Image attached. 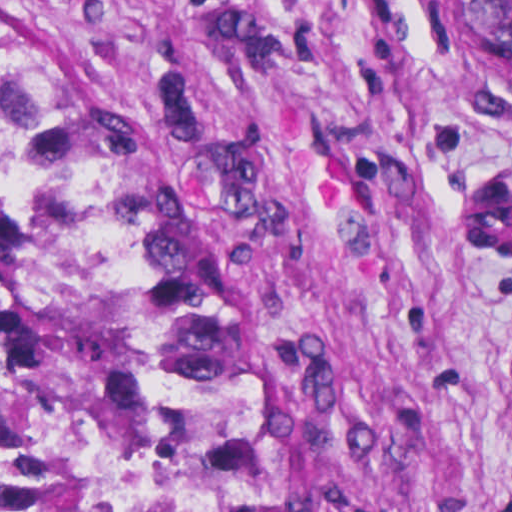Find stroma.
<instances>
[{"label":"stroma","instance_id":"1","mask_svg":"<svg viewBox=\"0 0 512 512\" xmlns=\"http://www.w3.org/2000/svg\"><path fill=\"white\" fill-rule=\"evenodd\" d=\"M0 47L232 324L300 512H512L479 0H0Z\"/></svg>","mask_w":512,"mask_h":512}]
</instances>
